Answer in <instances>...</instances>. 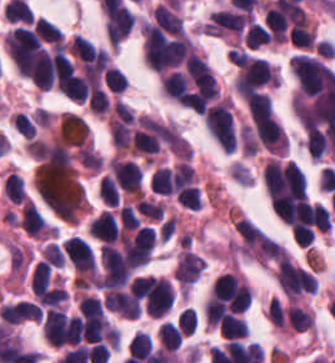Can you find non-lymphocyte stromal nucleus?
Returning <instances> with one entry per match:
<instances>
[{"instance_id": "dd21d789", "label": "non-lymphocyte stromal nucleus", "mask_w": 335, "mask_h": 363, "mask_svg": "<svg viewBox=\"0 0 335 363\" xmlns=\"http://www.w3.org/2000/svg\"><path fill=\"white\" fill-rule=\"evenodd\" d=\"M241 150L246 155H253L257 150V140L250 124H241L239 128Z\"/></svg>"}]
</instances>
